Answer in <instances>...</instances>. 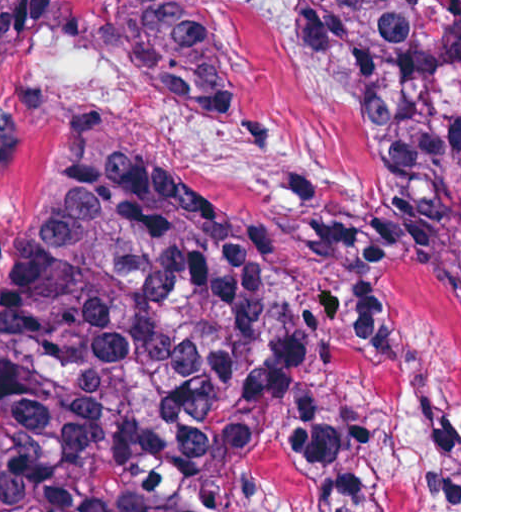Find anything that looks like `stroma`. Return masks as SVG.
Instances as JSON below:
<instances>
[{"instance_id":"obj_1","label":"stroma","mask_w":512,"mask_h":512,"mask_svg":"<svg viewBox=\"0 0 512 512\" xmlns=\"http://www.w3.org/2000/svg\"><path fill=\"white\" fill-rule=\"evenodd\" d=\"M0 91V273L24 252L70 176L78 136L119 158L191 168L237 216L280 237L300 290L345 278L306 246L307 225L360 217L387 197L378 124L312 53L295 0H197L221 33L248 117L233 133L145 93L103 27L101 0H71ZM412 345L362 359L319 319L330 390L395 512H461V0L459 268L401 265Z\"/></svg>"}]
</instances>
